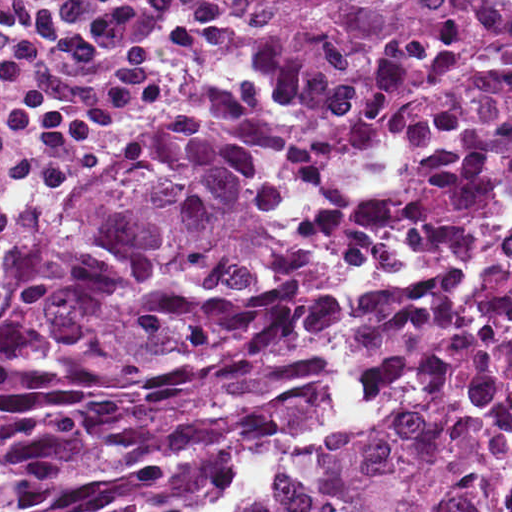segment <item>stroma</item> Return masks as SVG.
<instances>
[{"label":"stroma","instance_id":"obj_1","mask_svg":"<svg viewBox=\"0 0 512 512\" xmlns=\"http://www.w3.org/2000/svg\"><path fill=\"white\" fill-rule=\"evenodd\" d=\"M269 4L270 0H245L226 49L204 78L185 96L167 101L154 112L105 134L74 167L62 185L31 205L25 222L12 235L0 256V284L15 267L24 250L49 228L60 213L97 183L180 136L193 124L207 119L223 92L246 34L262 19ZM505 232H512V191L488 198L468 223L430 249L344 266L337 278L339 302L342 297L360 288L428 269ZM439 389L426 390L408 404L396 407L364 397L347 384L334 347L322 369L318 400L293 431L266 442L256 456L254 491L243 498L232 512H261L288 462L317 428L327 397L341 392L364 405L372 417H390L430 399Z\"/></svg>","mask_w":512,"mask_h":512}]
</instances>
